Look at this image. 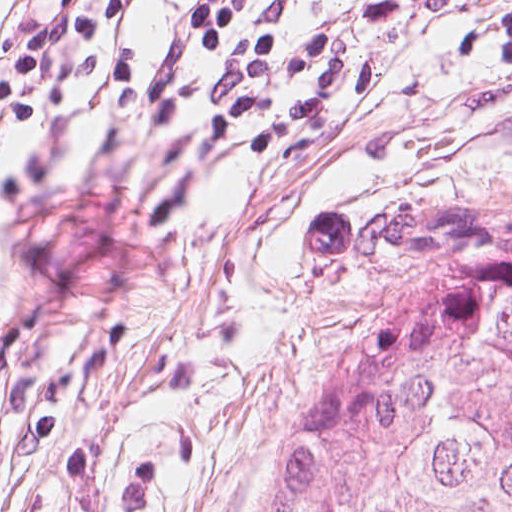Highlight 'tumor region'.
Instances as JSON below:
<instances>
[{
    "label": "tumor region",
    "instance_id": "e687c5a6",
    "mask_svg": "<svg viewBox=\"0 0 512 512\" xmlns=\"http://www.w3.org/2000/svg\"><path fill=\"white\" fill-rule=\"evenodd\" d=\"M305 234L338 293L271 512H512V206L408 186Z\"/></svg>",
    "mask_w": 512,
    "mask_h": 512
}]
</instances>
